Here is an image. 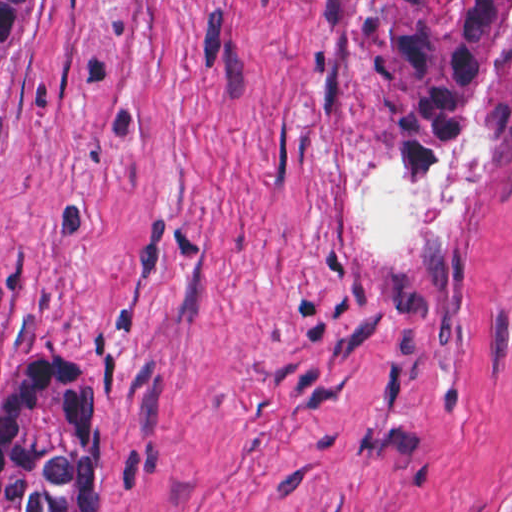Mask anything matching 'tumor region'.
Here are the masks:
<instances>
[{
    "mask_svg": "<svg viewBox=\"0 0 512 512\" xmlns=\"http://www.w3.org/2000/svg\"><path fill=\"white\" fill-rule=\"evenodd\" d=\"M31 1H0V72ZM314 89L411 168L470 175L474 132L512 109V1H330ZM103 472V380L27 350L0 388V512H86Z\"/></svg>",
    "mask_w": 512,
    "mask_h": 512,
    "instance_id": "obj_1",
    "label": "tumor region"
}]
</instances>
